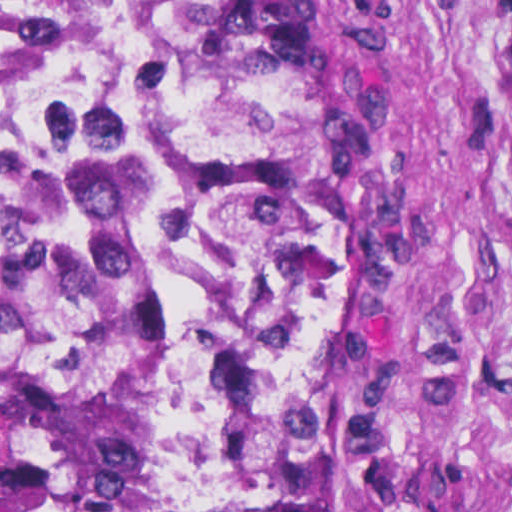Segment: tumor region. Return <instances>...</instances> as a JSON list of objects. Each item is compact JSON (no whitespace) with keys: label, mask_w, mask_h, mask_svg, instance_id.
I'll list each match as a JSON object with an SVG mask.
<instances>
[{"label":"tumor region","mask_w":512,"mask_h":512,"mask_svg":"<svg viewBox=\"0 0 512 512\" xmlns=\"http://www.w3.org/2000/svg\"><path fill=\"white\" fill-rule=\"evenodd\" d=\"M151 83L0 177V512H386L379 265L301 0H145Z\"/></svg>","instance_id":"1"}]
</instances>
